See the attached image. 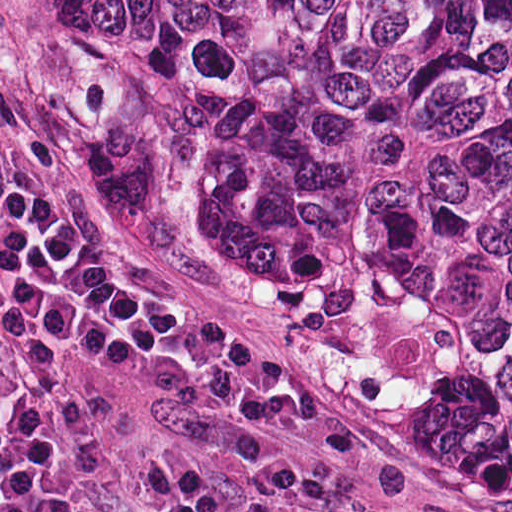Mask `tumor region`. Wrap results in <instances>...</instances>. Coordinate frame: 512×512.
Listing matches in <instances>:
<instances>
[{"instance_id":"obj_1","label":"tumor region","mask_w":512,"mask_h":512,"mask_svg":"<svg viewBox=\"0 0 512 512\" xmlns=\"http://www.w3.org/2000/svg\"><path fill=\"white\" fill-rule=\"evenodd\" d=\"M98 190L209 242L445 494L512 493V0H52Z\"/></svg>"}]
</instances>
